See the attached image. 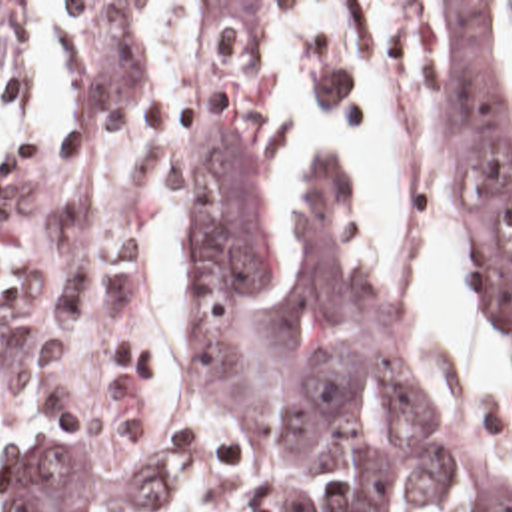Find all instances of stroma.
<instances>
[{"instance_id": "stroma-1", "label": "stroma", "mask_w": 512, "mask_h": 512, "mask_svg": "<svg viewBox=\"0 0 512 512\" xmlns=\"http://www.w3.org/2000/svg\"><path fill=\"white\" fill-rule=\"evenodd\" d=\"M47 2L17 18L0 48V84L17 30ZM131 2L55 0L69 118L0 186V421L17 435L87 443L107 469L155 459L173 477V503L161 511L77 512H267L245 449L215 421L191 361L195 274L185 295L187 367L147 315L153 222L169 212L189 256L187 158L201 114L229 104L257 134L279 62L281 16L305 74L355 106L361 62L331 26L349 30L401 80L415 154L461 200L453 10L457 2L512 0H195L199 102L177 94L129 28ZM421 395L433 421L512 507L511 487Z\"/></svg>"}]
</instances>
